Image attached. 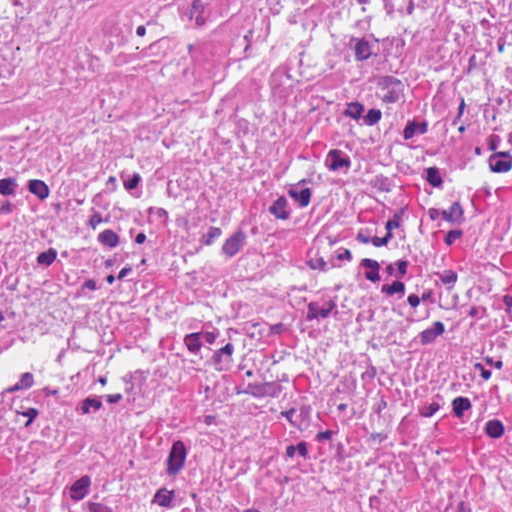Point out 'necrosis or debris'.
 Masks as SVG:
<instances>
[{
    "instance_id": "necrosis-or-debris-1",
    "label": "necrosis or debris",
    "mask_w": 512,
    "mask_h": 512,
    "mask_svg": "<svg viewBox=\"0 0 512 512\" xmlns=\"http://www.w3.org/2000/svg\"><path fill=\"white\" fill-rule=\"evenodd\" d=\"M1 512H512V0H1Z\"/></svg>"
}]
</instances>
